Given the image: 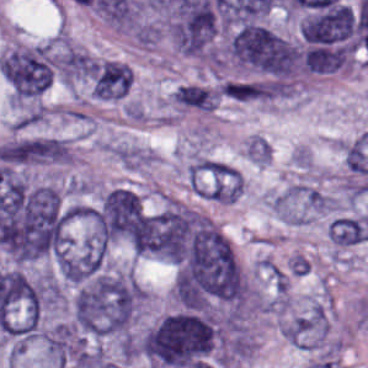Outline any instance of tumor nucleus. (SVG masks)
Masks as SVG:
<instances>
[{"label":"tumor nucleus","mask_w":368,"mask_h":368,"mask_svg":"<svg viewBox=\"0 0 368 368\" xmlns=\"http://www.w3.org/2000/svg\"><path fill=\"white\" fill-rule=\"evenodd\" d=\"M149 368H213L220 359L216 319L205 310L170 312L136 342Z\"/></svg>","instance_id":"tumor-nucleus-1"},{"label":"tumor nucleus","mask_w":368,"mask_h":368,"mask_svg":"<svg viewBox=\"0 0 368 368\" xmlns=\"http://www.w3.org/2000/svg\"><path fill=\"white\" fill-rule=\"evenodd\" d=\"M138 283L126 268L105 269L75 290L72 308L80 332L94 337H127L135 318Z\"/></svg>","instance_id":"tumor-nucleus-2"},{"label":"tumor nucleus","mask_w":368,"mask_h":368,"mask_svg":"<svg viewBox=\"0 0 368 368\" xmlns=\"http://www.w3.org/2000/svg\"><path fill=\"white\" fill-rule=\"evenodd\" d=\"M227 53L243 72L288 86L300 70V47L270 27L249 21L231 33Z\"/></svg>","instance_id":"tumor-nucleus-3"}]
</instances>
